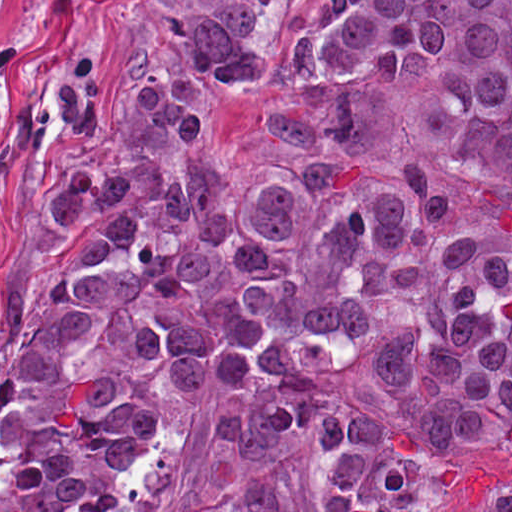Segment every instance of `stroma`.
I'll list each match as a JSON object with an SVG mask.
<instances>
[{
	"label": "stroma",
	"mask_w": 512,
	"mask_h": 512,
	"mask_svg": "<svg viewBox=\"0 0 512 512\" xmlns=\"http://www.w3.org/2000/svg\"><path fill=\"white\" fill-rule=\"evenodd\" d=\"M315 0H266L250 13L262 74L217 89V161L226 176L272 183L304 166L346 162L380 177L413 155L286 152L254 143L242 110L273 89L278 23ZM200 0H71L0 31V364L6 340L40 315L52 272L74 246L57 225L58 175L124 127L133 93L157 74L171 34ZM458 186L447 217L511 216L502 188L445 166Z\"/></svg>",
	"instance_id": "obj_1"
}]
</instances>
